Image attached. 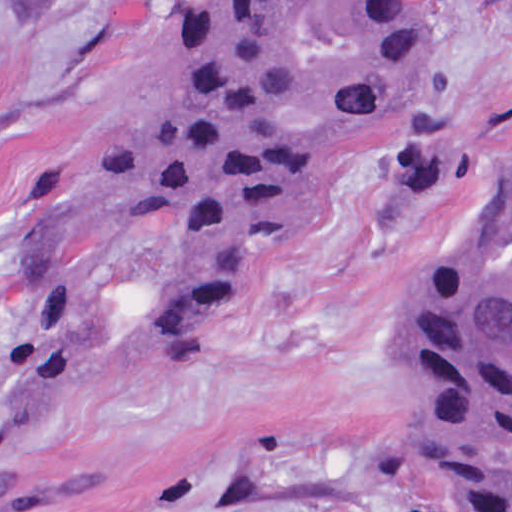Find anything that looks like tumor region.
<instances>
[{
  "instance_id": "obj_1",
  "label": "tumor region",
  "mask_w": 512,
  "mask_h": 512,
  "mask_svg": "<svg viewBox=\"0 0 512 512\" xmlns=\"http://www.w3.org/2000/svg\"><path fill=\"white\" fill-rule=\"evenodd\" d=\"M437 0H192L83 185L25 224L27 267L0 316V512L63 493L8 444L94 351L96 245L137 216L177 227L135 373L232 299L288 238L388 152L399 209L462 176L439 126ZM409 428L447 512H512V154L497 208L456 262L411 287L394 325Z\"/></svg>"
}]
</instances>
